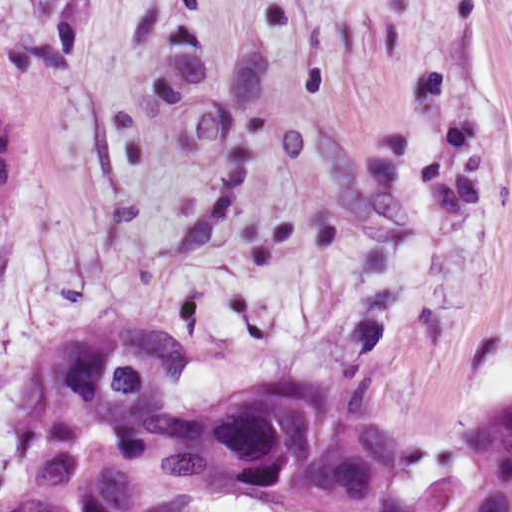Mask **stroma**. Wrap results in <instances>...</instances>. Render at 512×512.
Instances as JSON below:
<instances>
[{
  "instance_id": "stroma-1",
  "label": "stroma",
  "mask_w": 512,
  "mask_h": 512,
  "mask_svg": "<svg viewBox=\"0 0 512 512\" xmlns=\"http://www.w3.org/2000/svg\"><path fill=\"white\" fill-rule=\"evenodd\" d=\"M0 104V453L38 357L125 327L188 362L173 414L326 373L462 487L512 389V0H0Z\"/></svg>"
}]
</instances>
